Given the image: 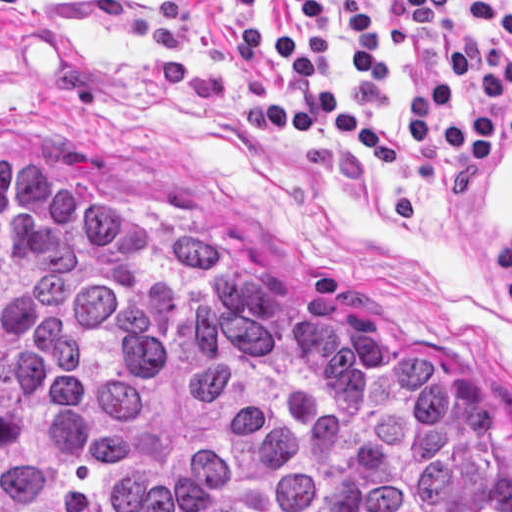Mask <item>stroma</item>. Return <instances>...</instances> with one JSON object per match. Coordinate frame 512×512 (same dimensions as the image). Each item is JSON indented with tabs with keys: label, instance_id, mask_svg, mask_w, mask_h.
<instances>
[{
	"label": "stroma",
	"instance_id": "stroma-1",
	"mask_svg": "<svg viewBox=\"0 0 512 512\" xmlns=\"http://www.w3.org/2000/svg\"><path fill=\"white\" fill-rule=\"evenodd\" d=\"M324 1L335 98L397 134L400 162H376L319 123L299 139L261 123L299 88L271 56L238 70L234 39L259 17L284 34L301 19L297 0L0 4V159L60 162L81 195L214 225L312 309L398 355H440L512 467V147L468 168L418 144L407 125L414 59L389 32L392 0H365L383 103L364 111L345 7ZM405 38L426 75L454 90V110L486 105L451 65L462 45L491 41L512 58V39L454 0L440 32Z\"/></svg>",
	"mask_w": 512,
	"mask_h": 512
}]
</instances>
